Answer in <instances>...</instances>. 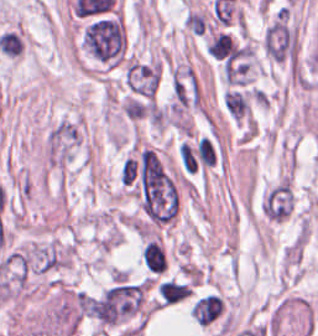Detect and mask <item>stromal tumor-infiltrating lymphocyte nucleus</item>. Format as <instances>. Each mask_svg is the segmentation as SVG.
Instances as JSON below:
<instances>
[{"mask_svg":"<svg viewBox=\"0 0 318 336\" xmlns=\"http://www.w3.org/2000/svg\"><path fill=\"white\" fill-rule=\"evenodd\" d=\"M160 302L169 304L189 295L191 288L186 281L166 278L156 287Z\"/></svg>","mask_w":318,"mask_h":336,"instance_id":"1","label":"stromal tumor-infiltrating lymphocyte nucleus"},{"mask_svg":"<svg viewBox=\"0 0 318 336\" xmlns=\"http://www.w3.org/2000/svg\"><path fill=\"white\" fill-rule=\"evenodd\" d=\"M141 257L151 271H162L167 266V259L162 243L149 239L141 248Z\"/></svg>","mask_w":318,"mask_h":336,"instance_id":"2","label":"stromal tumor-infiltrating lymphocyte nucleus"}]
</instances>
